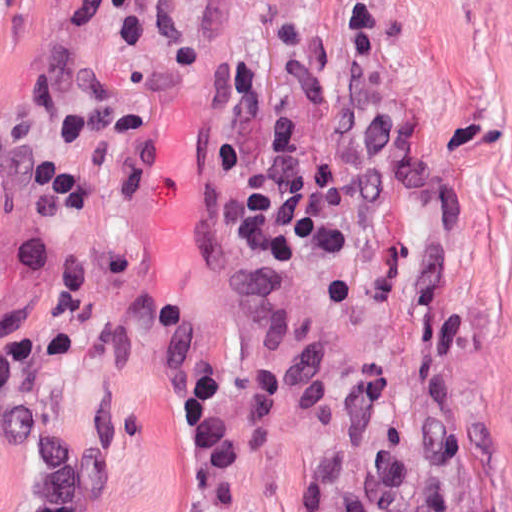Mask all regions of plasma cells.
<instances>
[{
    "label": "plasma cells",
    "mask_w": 512,
    "mask_h": 512,
    "mask_svg": "<svg viewBox=\"0 0 512 512\" xmlns=\"http://www.w3.org/2000/svg\"><path fill=\"white\" fill-rule=\"evenodd\" d=\"M34 1L59 29L97 35L131 68L170 71L188 66L194 55L184 0ZM259 89L251 66H228L227 109L205 143L228 233L267 279H282L301 260L331 266L349 258L358 230L382 220L393 202L394 114L381 104L341 105L329 115V126L342 150L316 156L303 152L293 126L276 115L266 119V147L253 158L242 127ZM34 182L42 216L18 250L29 271L60 291L48 322V348L57 356L135 363L142 348L137 326L106 305L94 268L58 233L94 204V193L61 162L41 165ZM30 329L22 309L0 316V438L37 478L34 500L13 512H88L87 452L19 372ZM174 407L192 452V484L180 512H223L240 444L221 413L213 351L180 373Z\"/></svg>",
    "instance_id": "9512152a"
}]
</instances>
